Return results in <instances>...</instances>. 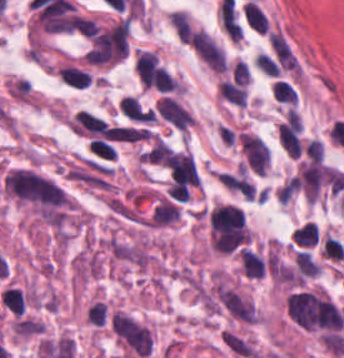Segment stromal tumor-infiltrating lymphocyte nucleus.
Here are the masks:
<instances>
[{
    "label": "stromal tumor-infiltrating lymphocyte nucleus",
    "mask_w": 344,
    "mask_h": 358,
    "mask_svg": "<svg viewBox=\"0 0 344 358\" xmlns=\"http://www.w3.org/2000/svg\"><path fill=\"white\" fill-rule=\"evenodd\" d=\"M1 299L13 314H22L25 310L24 293L20 287L6 286Z\"/></svg>",
    "instance_id": "1"
}]
</instances>
